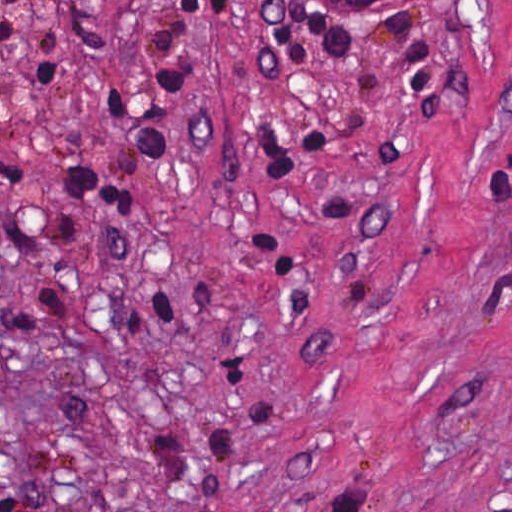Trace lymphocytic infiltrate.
I'll list each match as a JSON object with an SVG mask.
<instances>
[{"label":"lymphocytic infiltrate","mask_w":512,"mask_h":512,"mask_svg":"<svg viewBox=\"0 0 512 512\" xmlns=\"http://www.w3.org/2000/svg\"><path fill=\"white\" fill-rule=\"evenodd\" d=\"M73 1L15 0L5 20L11 54L34 91L54 84L61 23ZM203 68V0H138L116 109L71 164L75 184L108 225L144 219L156 205L166 154L190 126ZM47 218L0 154V223L55 234L32 225ZM0 512H55L48 479L15 482Z\"/></svg>","instance_id":"f902f5d3"}]
</instances>
